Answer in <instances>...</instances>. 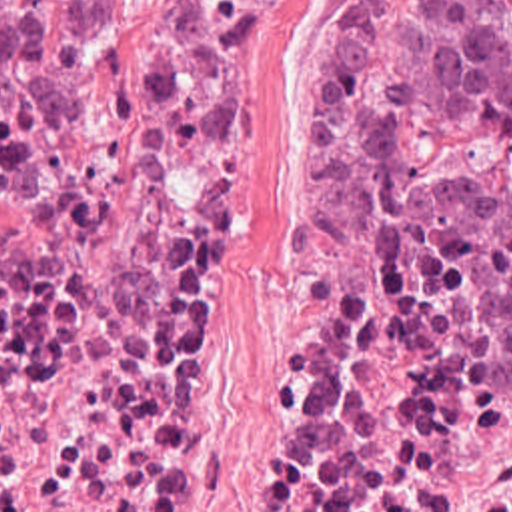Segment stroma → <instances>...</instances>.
Masks as SVG:
<instances>
[{
	"instance_id": "stroma-1",
	"label": "stroma",
	"mask_w": 512,
	"mask_h": 512,
	"mask_svg": "<svg viewBox=\"0 0 512 512\" xmlns=\"http://www.w3.org/2000/svg\"><path fill=\"white\" fill-rule=\"evenodd\" d=\"M343 0H273L229 73L221 169L225 267L203 305L201 369L169 439L159 512H247L267 411L277 285L307 225L309 137L327 25ZM165 0H129L95 25L87 77L121 57ZM403 199L445 203L512 193V135L439 129L389 183Z\"/></svg>"
}]
</instances>
